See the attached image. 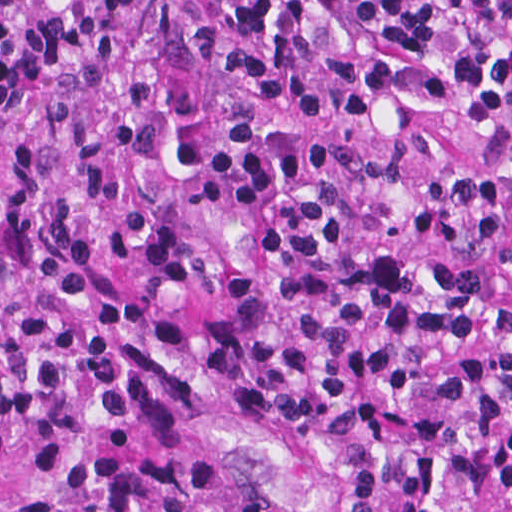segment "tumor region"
<instances>
[{
  "instance_id": "tumor-region-1",
  "label": "tumor region",
  "mask_w": 512,
  "mask_h": 512,
  "mask_svg": "<svg viewBox=\"0 0 512 512\" xmlns=\"http://www.w3.org/2000/svg\"><path fill=\"white\" fill-rule=\"evenodd\" d=\"M36 512H307L273 435L204 427Z\"/></svg>"
}]
</instances>
